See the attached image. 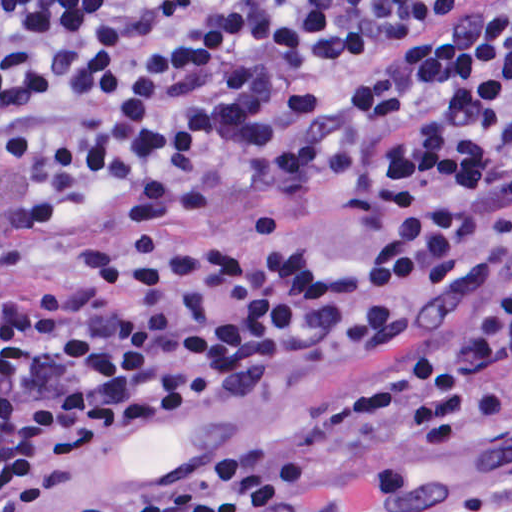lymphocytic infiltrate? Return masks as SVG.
Instances as JSON below:
<instances>
[{"instance_id": "1", "label": "lymphocytic infiltrate", "mask_w": 512, "mask_h": 512, "mask_svg": "<svg viewBox=\"0 0 512 512\" xmlns=\"http://www.w3.org/2000/svg\"><path fill=\"white\" fill-rule=\"evenodd\" d=\"M250 191L353 213L310 245L164 249L0 293V512L173 412L389 346L345 512H396L428 444L512 431V0H0V223L98 253ZM331 449L272 443L73 512H313ZM496 512H512V500Z\"/></svg>"}]
</instances>
